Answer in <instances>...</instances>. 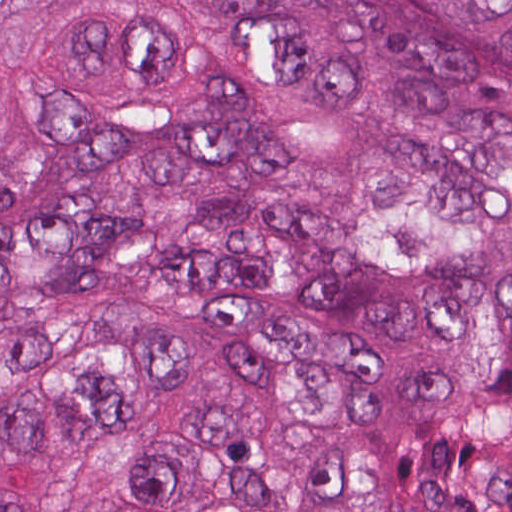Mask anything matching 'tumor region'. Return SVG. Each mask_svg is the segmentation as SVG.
Instances as JSON below:
<instances>
[{
  "mask_svg": "<svg viewBox=\"0 0 512 512\" xmlns=\"http://www.w3.org/2000/svg\"><path fill=\"white\" fill-rule=\"evenodd\" d=\"M0 512H512V0H0Z\"/></svg>",
  "mask_w": 512,
  "mask_h": 512,
  "instance_id": "1",
  "label": "tumor region"
}]
</instances>
